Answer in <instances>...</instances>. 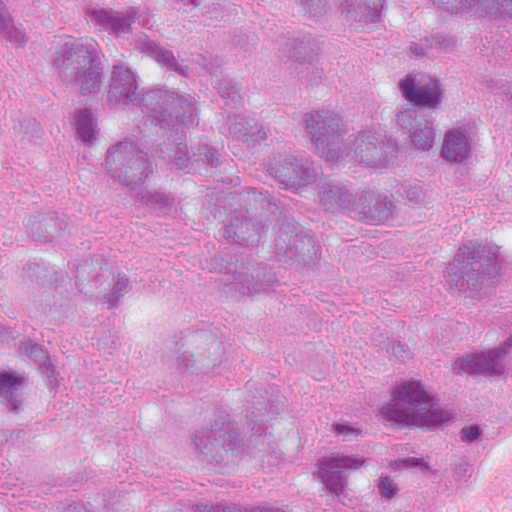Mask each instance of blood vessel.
I'll list each match as a JSON object with an SVG mask.
<instances>
[{
  "label": "blood vessel",
  "instance_id": "obj_1",
  "mask_svg": "<svg viewBox=\"0 0 512 512\" xmlns=\"http://www.w3.org/2000/svg\"><path fill=\"white\" fill-rule=\"evenodd\" d=\"M390 512H512V341L477 348L433 392Z\"/></svg>",
  "mask_w": 512,
  "mask_h": 512
}]
</instances>
